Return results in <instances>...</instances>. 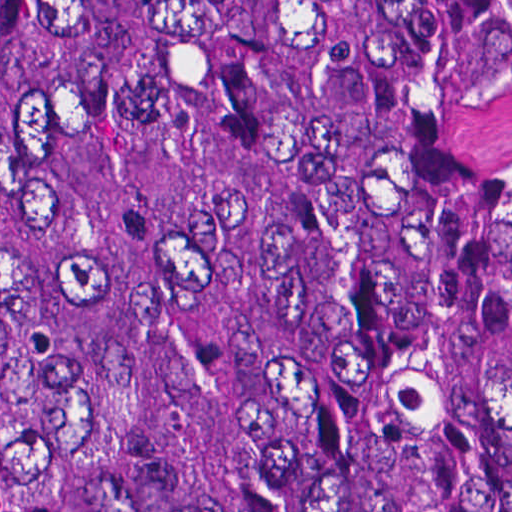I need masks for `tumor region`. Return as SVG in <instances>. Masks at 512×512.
<instances>
[{"mask_svg":"<svg viewBox=\"0 0 512 512\" xmlns=\"http://www.w3.org/2000/svg\"><path fill=\"white\" fill-rule=\"evenodd\" d=\"M0 512H512V0H0Z\"/></svg>","mask_w":512,"mask_h":512,"instance_id":"e687c5a6","label":"tumor region"}]
</instances>
